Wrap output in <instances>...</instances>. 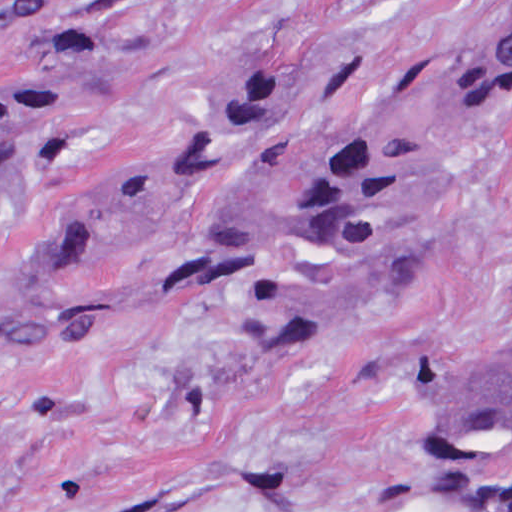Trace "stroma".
<instances>
[{"label":"stroma","mask_w":512,"mask_h":512,"mask_svg":"<svg viewBox=\"0 0 512 512\" xmlns=\"http://www.w3.org/2000/svg\"><path fill=\"white\" fill-rule=\"evenodd\" d=\"M511 0H85L68 28L0 20V97L116 65L59 161L0 210V282L133 171L218 80L306 79L251 175L304 193L350 136L403 150L428 201L407 282L343 353L286 338H0V512H512V461L459 484L425 465L415 362L512 340V117L481 109Z\"/></svg>","instance_id":"1"}]
</instances>
